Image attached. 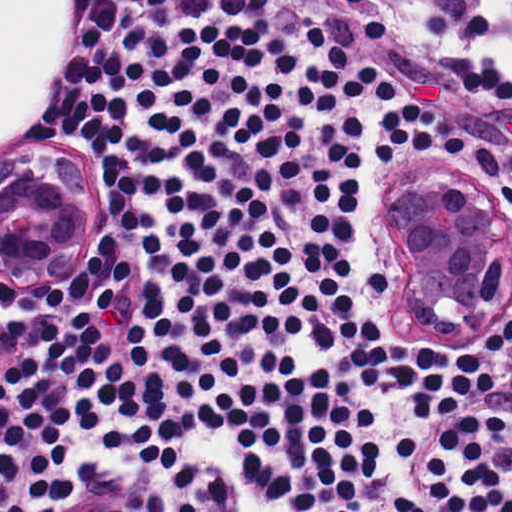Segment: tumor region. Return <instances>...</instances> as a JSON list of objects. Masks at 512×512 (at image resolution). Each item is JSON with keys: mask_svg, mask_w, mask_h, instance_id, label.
<instances>
[{"mask_svg": "<svg viewBox=\"0 0 512 512\" xmlns=\"http://www.w3.org/2000/svg\"><path fill=\"white\" fill-rule=\"evenodd\" d=\"M95 214L78 162L33 156L1 160V263L38 272L75 250Z\"/></svg>", "mask_w": 512, "mask_h": 512, "instance_id": "e687c5a6", "label": "tumor region"}]
</instances>
